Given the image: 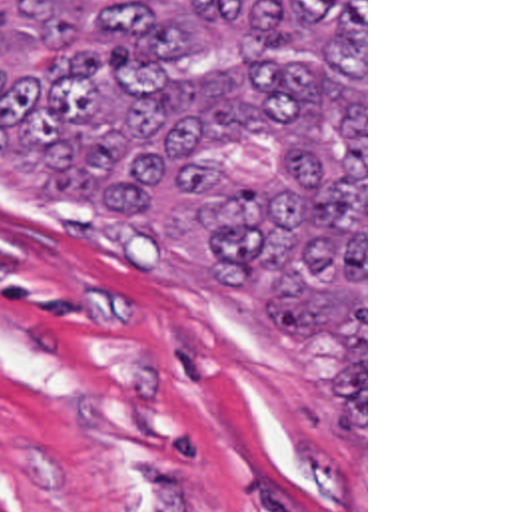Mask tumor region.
Listing matches in <instances>:
<instances>
[{
  "mask_svg": "<svg viewBox=\"0 0 512 512\" xmlns=\"http://www.w3.org/2000/svg\"><path fill=\"white\" fill-rule=\"evenodd\" d=\"M0 169L196 237L264 341L344 343L364 422V0L7 1Z\"/></svg>",
  "mask_w": 512,
  "mask_h": 512,
  "instance_id": "1",
  "label": "tumor region"
}]
</instances>
